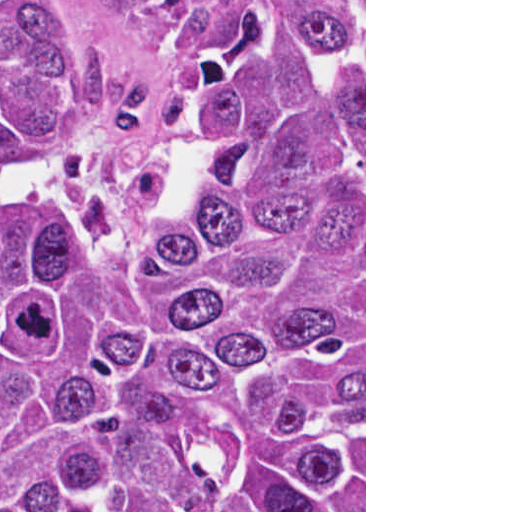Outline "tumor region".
I'll use <instances>...</instances> for the list:
<instances>
[{"label":"tumor region","mask_w":512,"mask_h":512,"mask_svg":"<svg viewBox=\"0 0 512 512\" xmlns=\"http://www.w3.org/2000/svg\"><path fill=\"white\" fill-rule=\"evenodd\" d=\"M93 47L87 0H0V512H364V5L241 0L133 220L3 172L99 137Z\"/></svg>","instance_id":"e687c5a6"}]
</instances>
